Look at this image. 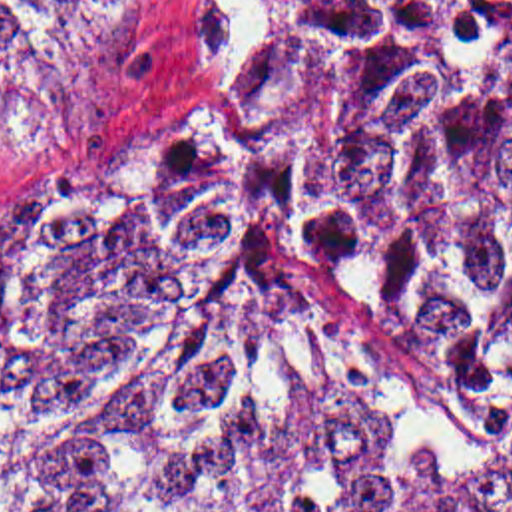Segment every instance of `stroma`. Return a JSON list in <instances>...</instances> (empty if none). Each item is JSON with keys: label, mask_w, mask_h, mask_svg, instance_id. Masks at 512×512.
Wrapping results in <instances>:
<instances>
[{"label": "stroma", "mask_w": 512, "mask_h": 512, "mask_svg": "<svg viewBox=\"0 0 512 512\" xmlns=\"http://www.w3.org/2000/svg\"><path fill=\"white\" fill-rule=\"evenodd\" d=\"M264 79V24L250 0H124L114 22L39 81L0 85V185L82 145L118 137H206L242 161L287 263L363 470L393 486L512 474L503 430L459 384L375 352L319 286L299 233L248 159Z\"/></svg>", "instance_id": "1"}]
</instances>
